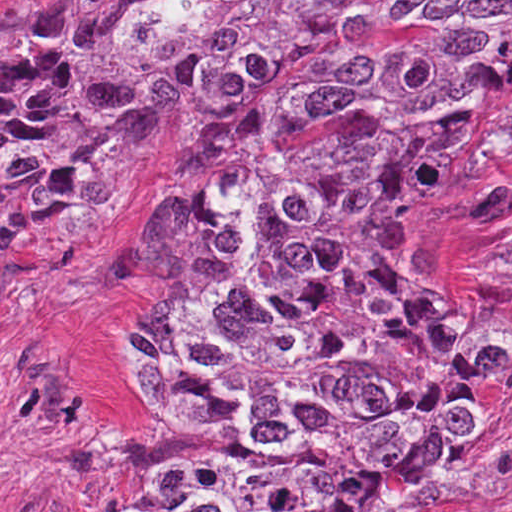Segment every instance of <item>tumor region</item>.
<instances>
[{"label":"tumor region","instance_id":"obj_1","mask_svg":"<svg viewBox=\"0 0 512 512\" xmlns=\"http://www.w3.org/2000/svg\"><path fill=\"white\" fill-rule=\"evenodd\" d=\"M72 0L0 20V281L125 192L146 105L203 118L146 229L135 362L205 439L97 512H439L512 322L415 286L512 169V0Z\"/></svg>","mask_w":512,"mask_h":512}]
</instances>
